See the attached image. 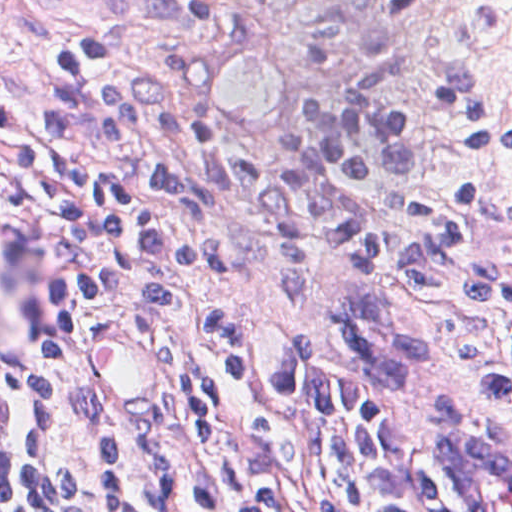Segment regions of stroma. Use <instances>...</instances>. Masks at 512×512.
I'll return each mask as SVG.
<instances>
[{"instance_id": "35a3bbf8", "label": "stroma", "mask_w": 512, "mask_h": 512, "mask_svg": "<svg viewBox=\"0 0 512 512\" xmlns=\"http://www.w3.org/2000/svg\"><path fill=\"white\" fill-rule=\"evenodd\" d=\"M66 32H94L169 57L243 148L287 152L303 147L309 113L327 88L337 95L387 56L435 59L477 80L512 122V0H0V360L47 411L57 461L55 512H84L93 426L127 422L107 408L92 381L88 345L98 320L114 316L143 325L172 353L170 389L147 422L189 412L193 389L149 318L102 307L74 327L46 304L49 218L19 160L17 88L48 41ZM237 40L269 45L290 82L287 119L267 140L236 135L213 100L210 62L216 50ZM399 87L421 110L424 163L398 186L380 181L381 192L406 201H441L456 187L512 196V154L463 151L448 137L434 101L412 81ZM465 230L477 248L512 269V231L480 217L469 219ZM223 255L241 274L189 291L249 334L261 356L309 337L319 353L348 357V337L337 320V307L351 294V258L343 249L313 243L308 282L293 300L278 296L277 247L268 238L230 236ZM440 425L512 447V413L439 398L422 411V508L457 512L436 465Z\"/></svg>"}]
</instances>
